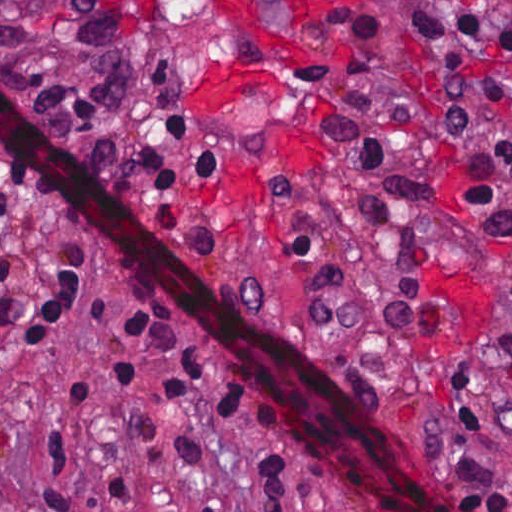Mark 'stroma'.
Listing matches in <instances>:
<instances>
[{"label":"stroma","mask_w":512,"mask_h":512,"mask_svg":"<svg viewBox=\"0 0 512 512\" xmlns=\"http://www.w3.org/2000/svg\"><path fill=\"white\" fill-rule=\"evenodd\" d=\"M408 1L422 0H356L315 14L265 0L302 48L283 71V99L189 106L191 70L256 64L266 48L225 23L214 0H115L135 98L140 65V110L127 184L129 149L111 186L176 256L294 344L319 382L327 369L356 424L436 512H473L454 484L494 474L507 479L512 509V441L497 436L512 265L472 205L468 148L441 119L437 92L469 78L512 82V49L419 39ZM167 110L192 119L180 147L217 151L218 168L154 197L140 156L163 152ZM63 241L89 303L51 340L22 346ZM0 265V299L27 315L0 334V512L35 505L48 401L77 386L100 399L64 467L87 511L118 480L129 499L109 512H266L244 483L262 472L261 440L225 422L203 392L159 397L102 378L96 329L135 308L183 321L131 256L35 192L0 230ZM460 357L477 433L437 444L431 460L419 447L441 422ZM237 377L285 424L257 383ZM291 430L346 485L307 483V510L392 512Z\"/></svg>","instance_id":"obj_1"}]
</instances>
